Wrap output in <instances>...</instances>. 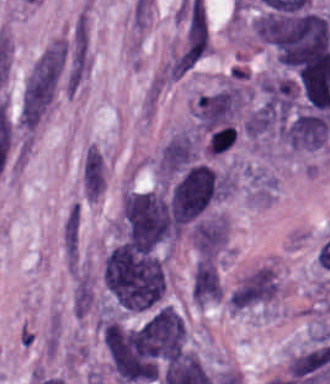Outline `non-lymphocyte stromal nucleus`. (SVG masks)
Instances as JSON below:
<instances>
[{
  "instance_id": "obj_2",
  "label": "non-lymphocyte stromal nucleus",
  "mask_w": 330,
  "mask_h": 384,
  "mask_svg": "<svg viewBox=\"0 0 330 384\" xmlns=\"http://www.w3.org/2000/svg\"><path fill=\"white\" fill-rule=\"evenodd\" d=\"M277 294V279L269 264L242 276L226 300L230 310H245L268 305Z\"/></svg>"
},
{
  "instance_id": "obj_3",
  "label": "non-lymphocyte stromal nucleus",
  "mask_w": 330,
  "mask_h": 384,
  "mask_svg": "<svg viewBox=\"0 0 330 384\" xmlns=\"http://www.w3.org/2000/svg\"><path fill=\"white\" fill-rule=\"evenodd\" d=\"M193 282L205 306L221 288L216 263L199 260Z\"/></svg>"
},
{
  "instance_id": "obj_7",
  "label": "non-lymphocyte stromal nucleus",
  "mask_w": 330,
  "mask_h": 384,
  "mask_svg": "<svg viewBox=\"0 0 330 384\" xmlns=\"http://www.w3.org/2000/svg\"><path fill=\"white\" fill-rule=\"evenodd\" d=\"M79 242V208H72L62 229V243L68 262H75Z\"/></svg>"
},
{
  "instance_id": "obj_1",
  "label": "non-lymphocyte stromal nucleus",
  "mask_w": 330,
  "mask_h": 384,
  "mask_svg": "<svg viewBox=\"0 0 330 384\" xmlns=\"http://www.w3.org/2000/svg\"><path fill=\"white\" fill-rule=\"evenodd\" d=\"M67 64L64 42L53 40L31 66L23 87L21 110L26 115L45 114L51 105Z\"/></svg>"
},
{
  "instance_id": "obj_6",
  "label": "non-lymphocyte stromal nucleus",
  "mask_w": 330,
  "mask_h": 384,
  "mask_svg": "<svg viewBox=\"0 0 330 384\" xmlns=\"http://www.w3.org/2000/svg\"><path fill=\"white\" fill-rule=\"evenodd\" d=\"M165 77L163 72H156L147 82L143 97L140 103L141 120L150 123L162 92L164 90Z\"/></svg>"
},
{
  "instance_id": "obj_4",
  "label": "non-lymphocyte stromal nucleus",
  "mask_w": 330,
  "mask_h": 384,
  "mask_svg": "<svg viewBox=\"0 0 330 384\" xmlns=\"http://www.w3.org/2000/svg\"><path fill=\"white\" fill-rule=\"evenodd\" d=\"M105 171L84 151L81 164L83 195L89 197L103 193Z\"/></svg>"
},
{
  "instance_id": "obj_5",
  "label": "non-lymphocyte stromal nucleus",
  "mask_w": 330,
  "mask_h": 384,
  "mask_svg": "<svg viewBox=\"0 0 330 384\" xmlns=\"http://www.w3.org/2000/svg\"><path fill=\"white\" fill-rule=\"evenodd\" d=\"M93 302V288L88 273L78 272L72 287V314L79 319L86 314Z\"/></svg>"
}]
</instances>
